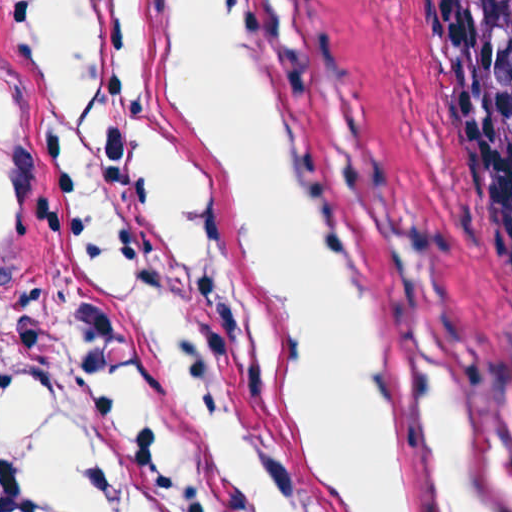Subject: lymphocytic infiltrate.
I'll return each instance as SVG.
<instances>
[{"label":"lymphocytic infiltrate","instance_id":"f902f5d3","mask_svg":"<svg viewBox=\"0 0 512 512\" xmlns=\"http://www.w3.org/2000/svg\"><path fill=\"white\" fill-rule=\"evenodd\" d=\"M38 381L50 397L85 384H128L143 424L101 464L97 512H319L294 433L240 416L188 364L138 268L65 217L30 321L1 370V407ZM1 512L48 505L1 441Z\"/></svg>","mask_w":512,"mask_h":512}]
</instances>
